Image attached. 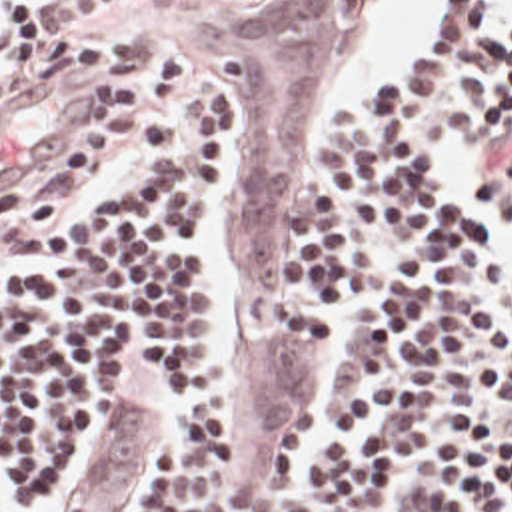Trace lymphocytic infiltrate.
<instances>
[{
    "mask_svg": "<svg viewBox=\"0 0 512 512\" xmlns=\"http://www.w3.org/2000/svg\"><path fill=\"white\" fill-rule=\"evenodd\" d=\"M58 29L0 0V73ZM124 189L0 263V512H56L100 413L136 385L166 411L150 512H226L228 389L210 347L214 191L232 159L212 81L140 121ZM302 189V303L382 309L360 331L314 512H512V19L456 0L424 63L344 117ZM136 383V385H134Z\"/></svg>",
    "mask_w": 512,
    "mask_h": 512,
    "instance_id": "1",
    "label": "lymphocytic infiltrate"
}]
</instances>
